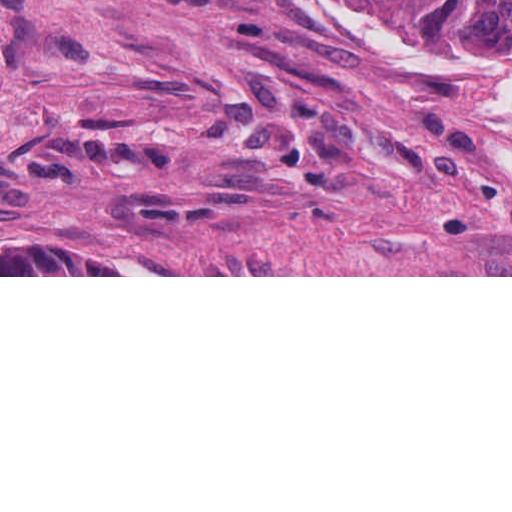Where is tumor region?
<instances>
[{"label": "tumor region", "instance_id": "obj_1", "mask_svg": "<svg viewBox=\"0 0 512 512\" xmlns=\"http://www.w3.org/2000/svg\"><path fill=\"white\" fill-rule=\"evenodd\" d=\"M411 27L512 44V0H375Z\"/></svg>", "mask_w": 512, "mask_h": 512}]
</instances>
